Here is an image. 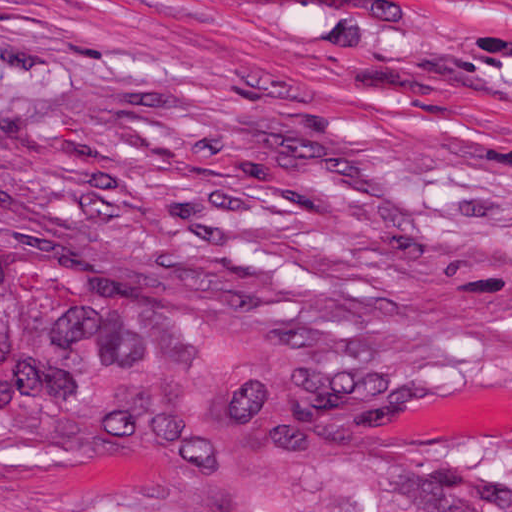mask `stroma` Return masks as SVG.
I'll return each mask as SVG.
<instances>
[{"label": "stroma", "instance_id": "1", "mask_svg": "<svg viewBox=\"0 0 512 512\" xmlns=\"http://www.w3.org/2000/svg\"><path fill=\"white\" fill-rule=\"evenodd\" d=\"M1 261L259 306L512 484V0H0V512H203L1 426Z\"/></svg>", "mask_w": 512, "mask_h": 512}]
</instances>
